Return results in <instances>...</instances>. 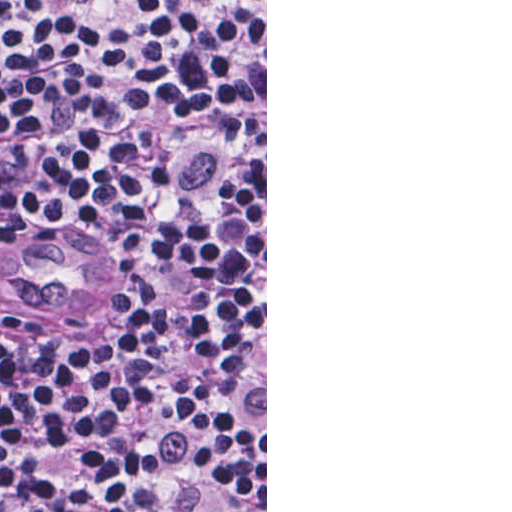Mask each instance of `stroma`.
<instances>
[{"label":"stroma","instance_id":"stroma-1","mask_svg":"<svg viewBox=\"0 0 512 512\" xmlns=\"http://www.w3.org/2000/svg\"><path fill=\"white\" fill-rule=\"evenodd\" d=\"M0 1H265V512H267V0H0Z\"/></svg>","mask_w":512,"mask_h":512}]
</instances>
